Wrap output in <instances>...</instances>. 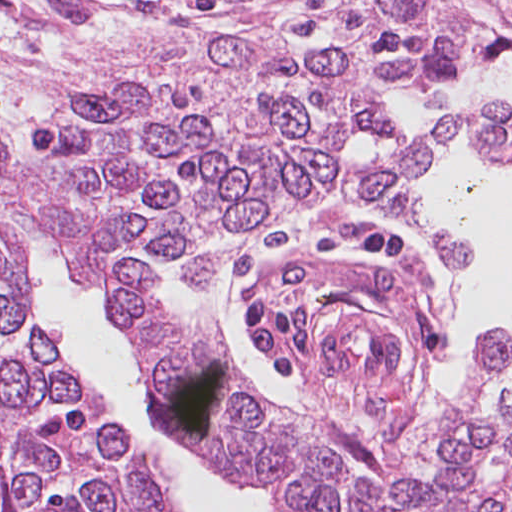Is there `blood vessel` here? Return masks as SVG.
<instances>
[{
  "mask_svg": "<svg viewBox=\"0 0 512 512\" xmlns=\"http://www.w3.org/2000/svg\"><path fill=\"white\" fill-rule=\"evenodd\" d=\"M321 356L354 376H386L398 365V346L387 319L358 302L324 330Z\"/></svg>",
  "mask_w": 512,
  "mask_h": 512,
  "instance_id": "8fb6f2fc",
  "label": "blood vessel"
}]
</instances>
